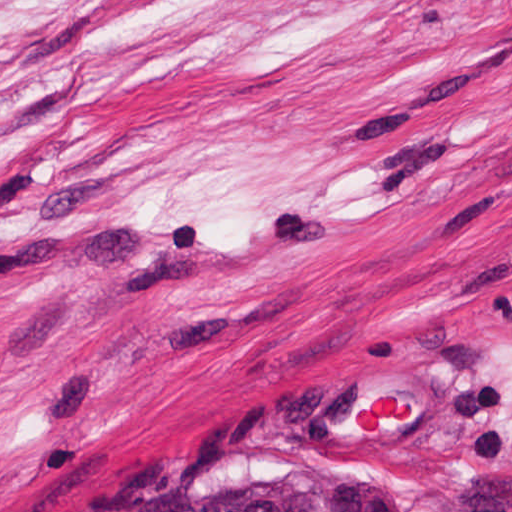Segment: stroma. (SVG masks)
Segmentation results:
<instances>
[{"instance_id": "35a3bbf8", "label": "stroma", "mask_w": 512, "mask_h": 512, "mask_svg": "<svg viewBox=\"0 0 512 512\" xmlns=\"http://www.w3.org/2000/svg\"><path fill=\"white\" fill-rule=\"evenodd\" d=\"M251 463L512 512V0H0V512Z\"/></svg>"}]
</instances>
